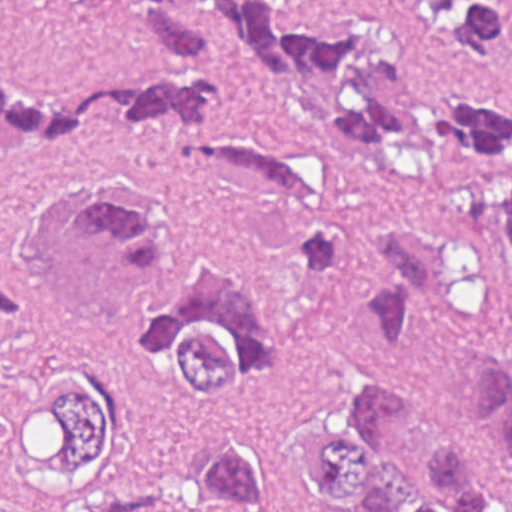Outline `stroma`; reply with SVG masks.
<instances>
[{
	"instance_id": "35a3bbf8",
	"label": "stroma",
	"mask_w": 512,
	"mask_h": 512,
	"mask_svg": "<svg viewBox=\"0 0 512 512\" xmlns=\"http://www.w3.org/2000/svg\"><path fill=\"white\" fill-rule=\"evenodd\" d=\"M387 2L421 54L463 88L512 108L511 63L479 54ZM478 2L488 18L512 27V0ZM223 58L229 118L283 145L337 186L353 234V254L343 270L316 282L298 275L295 257L310 227L302 210L200 182L184 169L183 128L101 104L67 147L38 156L0 151V276L25 282L33 272L20 248L27 216L62 187L126 166L111 178L147 195L183 230L234 251L283 338L278 376L260 396L238 404L153 399L156 418L178 443L191 448L217 435L295 434L350 384L381 374L418 378L459 407L475 409L467 396L479 335L456 305H432L418 314L390 352L369 348L362 329L377 229L439 217L435 197L342 152L330 136L326 97L286 89ZM0 73L46 96H85L144 73L184 80L181 67L138 39L122 0H2ZM283 511L338 512L313 495ZM0 512H62L30 490L1 443Z\"/></svg>"
}]
</instances>
